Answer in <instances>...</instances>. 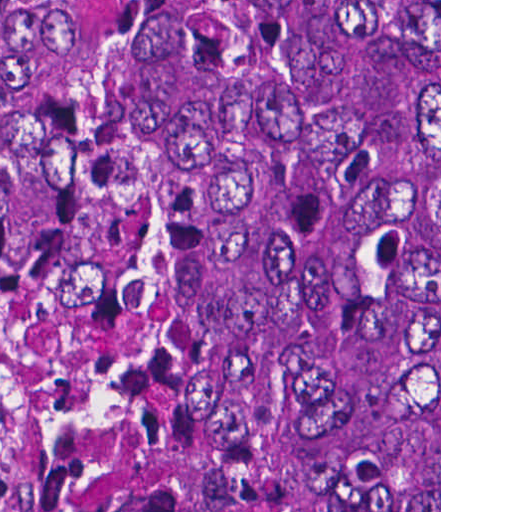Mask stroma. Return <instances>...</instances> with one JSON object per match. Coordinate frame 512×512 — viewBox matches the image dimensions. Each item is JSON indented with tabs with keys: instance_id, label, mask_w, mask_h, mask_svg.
I'll list each match as a JSON object with an SVG mask.
<instances>
[{
	"instance_id": "obj_1",
	"label": "stroma",
	"mask_w": 512,
	"mask_h": 512,
	"mask_svg": "<svg viewBox=\"0 0 512 512\" xmlns=\"http://www.w3.org/2000/svg\"><path fill=\"white\" fill-rule=\"evenodd\" d=\"M49 322V0H0V342L38 376ZM441 512V0H439Z\"/></svg>"
}]
</instances>
